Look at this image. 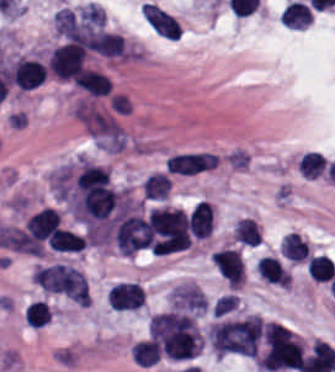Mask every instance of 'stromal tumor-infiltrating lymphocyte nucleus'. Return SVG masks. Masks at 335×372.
Returning a JSON list of instances; mask_svg holds the SVG:
<instances>
[{
	"instance_id": "f3e2335f",
	"label": "stromal tumor-infiltrating lymphocyte nucleus",
	"mask_w": 335,
	"mask_h": 372,
	"mask_svg": "<svg viewBox=\"0 0 335 372\" xmlns=\"http://www.w3.org/2000/svg\"><path fill=\"white\" fill-rule=\"evenodd\" d=\"M72 83L89 96H103L111 91L107 78L90 68H83Z\"/></svg>"
},
{
	"instance_id": "2a367800",
	"label": "stromal tumor-infiltrating lymphocyte nucleus",
	"mask_w": 335,
	"mask_h": 372,
	"mask_svg": "<svg viewBox=\"0 0 335 372\" xmlns=\"http://www.w3.org/2000/svg\"><path fill=\"white\" fill-rule=\"evenodd\" d=\"M281 253L289 262L303 263L309 247L297 232H289L281 243Z\"/></svg>"
},
{
	"instance_id": "abfb95fc",
	"label": "stromal tumor-infiltrating lymphocyte nucleus",
	"mask_w": 335,
	"mask_h": 372,
	"mask_svg": "<svg viewBox=\"0 0 335 372\" xmlns=\"http://www.w3.org/2000/svg\"><path fill=\"white\" fill-rule=\"evenodd\" d=\"M191 235L209 237L214 226V208L208 201H200L193 206L188 217Z\"/></svg>"
},
{
	"instance_id": "3290ff9b",
	"label": "stromal tumor-infiltrating lymphocyte nucleus",
	"mask_w": 335,
	"mask_h": 372,
	"mask_svg": "<svg viewBox=\"0 0 335 372\" xmlns=\"http://www.w3.org/2000/svg\"><path fill=\"white\" fill-rule=\"evenodd\" d=\"M60 225V216L51 208H44L25 222V230L35 238L52 241Z\"/></svg>"
},
{
	"instance_id": "bc302bb0",
	"label": "stromal tumor-infiltrating lymphocyte nucleus",
	"mask_w": 335,
	"mask_h": 372,
	"mask_svg": "<svg viewBox=\"0 0 335 372\" xmlns=\"http://www.w3.org/2000/svg\"><path fill=\"white\" fill-rule=\"evenodd\" d=\"M87 50L72 43H65L51 52L47 68L62 79H73L85 68Z\"/></svg>"
},
{
	"instance_id": "52c7bb5b",
	"label": "stromal tumor-infiltrating lymphocyte nucleus",
	"mask_w": 335,
	"mask_h": 372,
	"mask_svg": "<svg viewBox=\"0 0 335 372\" xmlns=\"http://www.w3.org/2000/svg\"><path fill=\"white\" fill-rule=\"evenodd\" d=\"M10 72L12 82L19 90H31L44 82L46 67L35 60L18 57Z\"/></svg>"
},
{
	"instance_id": "2761f720",
	"label": "stromal tumor-infiltrating lymphocyte nucleus",
	"mask_w": 335,
	"mask_h": 372,
	"mask_svg": "<svg viewBox=\"0 0 335 372\" xmlns=\"http://www.w3.org/2000/svg\"><path fill=\"white\" fill-rule=\"evenodd\" d=\"M234 236L241 244L254 247L261 238L256 221L246 216L237 220Z\"/></svg>"
},
{
	"instance_id": "4c9ddf68",
	"label": "stromal tumor-infiltrating lymphocyte nucleus",
	"mask_w": 335,
	"mask_h": 372,
	"mask_svg": "<svg viewBox=\"0 0 335 372\" xmlns=\"http://www.w3.org/2000/svg\"><path fill=\"white\" fill-rule=\"evenodd\" d=\"M26 326L41 328L51 321L50 306L46 301L35 300L24 311Z\"/></svg>"
},
{
	"instance_id": "4245b91a",
	"label": "stromal tumor-infiltrating lymphocyte nucleus",
	"mask_w": 335,
	"mask_h": 372,
	"mask_svg": "<svg viewBox=\"0 0 335 372\" xmlns=\"http://www.w3.org/2000/svg\"><path fill=\"white\" fill-rule=\"evenodd\" d=\"M327 160L324 153L305 152L298 162L300 174L305 178H317L325 169Z\"/></svg>"
},
{
	"instance_id": "9ea309e8",
	"label": "stromal tumor-infiltrating lymphocyte nucleus",
	"mask_w": 335,
	"mask_h": 372,
	"mask_svg": "<svg viewBox=\"0 0 335 372\" xmlns=\"http://www.w3.org/2000/svg\"><path fill=\"white\" fill-rule=\"evenodd\" d=\"M257 274L263 279L289 288L292 276L276 256L258 258Z\"/></svg>"
},
{
	"instance_id": "4803ca6d",
	"label": "stromal tumor-infiltrating lymphocyte nucleus",
	"mask_w": 335,
	"mask_h": 372,
	"mask_svg": "<svg viewBox=\"0 0 335 372\" xmlns=\"http://www.w3.org/2000/svg\"><path fill=\"white\" fill-rule=\"evenodd\" d=\"M47 244L56 252H81L85 240L82 236L59 229Z\"/></svg>"
},
{
	"instance_id": "4f13568d",
	"label": "stromal tumor-infiltrating lymphocyte nucleus",
	"mask_w": 335,
	"mask_h": 372,
	"mask_svg": "<svg viewBox=\"0 0 335 372\" xmlns=\"http://www.w3.org/2000/svg\"><path fill=\"white\" fill-rule=\"evenodd\" d=\"M313 13L308 4L297 0H289L284 7L280 21L291 28H305Z\"/></svg>"
}]
</instances>
